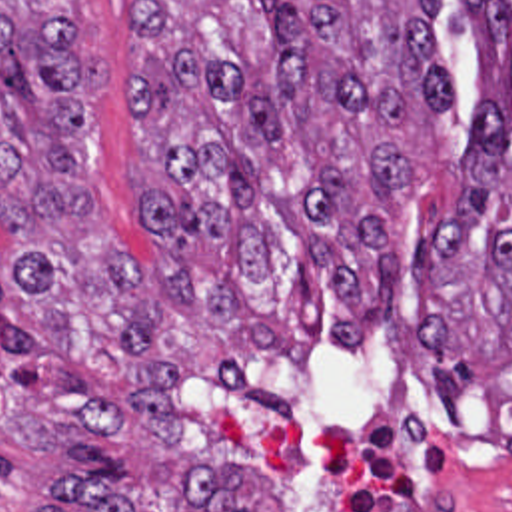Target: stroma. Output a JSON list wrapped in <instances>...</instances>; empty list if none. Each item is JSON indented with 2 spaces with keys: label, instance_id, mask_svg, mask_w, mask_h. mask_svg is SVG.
<instances>
[{
  "label": "stroma",
  "instance_id": "1",
  "mask_svg": "<svg viewBox=\"0 0 512 512\" xmlns=\"http://www.w3.org/2000/svg\"><path fill=\"white\" fill-rule=\"evenodd\" d=\"M433 28L455 104L409 124L415 182L389 212V248L405 258L389 330L371 336L359 358L325 344L305 364L281 366L181 310L161 274L147 356L183 372L179 441L157 447L141 428L103 436L0 358V512H79L57 495L59 481L79 477L73 471L109 477L133 511L209 512L183 489L195 461L239 469V497L253 512H512L511 404L453 394L451 416L423 390L427 306L417 254L431 226L453 218L465 198L457 160L471 142L479 68L467 0H443ZM69 32L97 72L79 128L81 176L129 278H143L155 254L139 198L159 178V150L127 106L139 0H71Z\"/></svg>",
  "mask_w": 512,
  "mask_h": 512
}]
</instances>
